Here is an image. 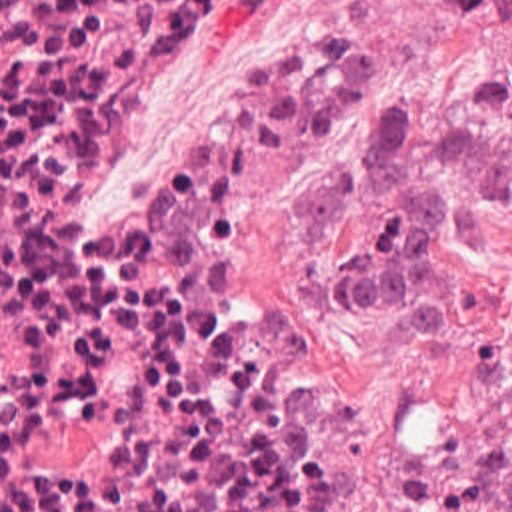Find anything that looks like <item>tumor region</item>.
<instances>
[{
  "mask_svg": "<svg viewBox=\"0 0 512 512\" xmlns=\"http://www.w3.org/2000/svg\"><path fill=\"white\" fill-rule=\"evenodd\" d=\"M458 14L492 12L512 26V0H450ZM512 199V137L422 108L396 88L368 104L358 143L302 183L300 221L322 233L372 205L368 243L320 265L306 305L336 321L380 315L412 345L456 335L450 257L486 249ZM492 512H512V451L492 491Z\"/></svg>",
  "mask_w": 512,
  "mask_h": 512,
  "instance_id": "e687c5a6",
  "label": "tumor region"
}]
</instances>
